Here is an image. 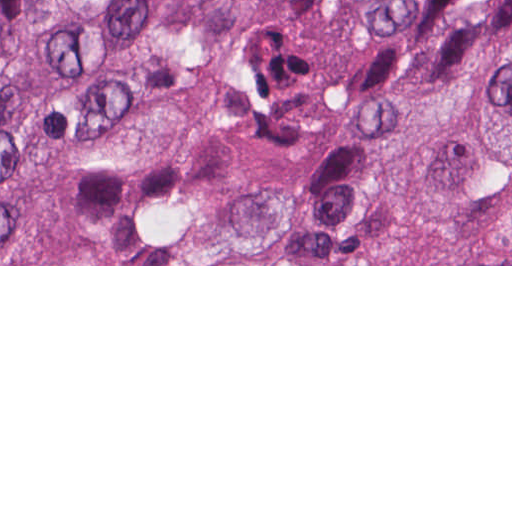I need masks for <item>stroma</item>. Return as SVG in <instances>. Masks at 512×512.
I'll list each match as a JSON object with an SVG mask.
<instances>
[{"instance_id": "stroma-1", "label": "stroma", "mask_w": 512, "mask_h": 512, "mask_svg": "<svg viewBox=\"0 0 512 512\" xmlns=\"http://www.w3.org/2000/svg\"><path fill=\"white\" fill-rule=\"evenodd\" d=\"M70 192V191H69ZM69 192L51 208L45 229V253L38 263L0 266H512V265H134L109 262L63 225Z\"/></svg>"}]
</instances>
